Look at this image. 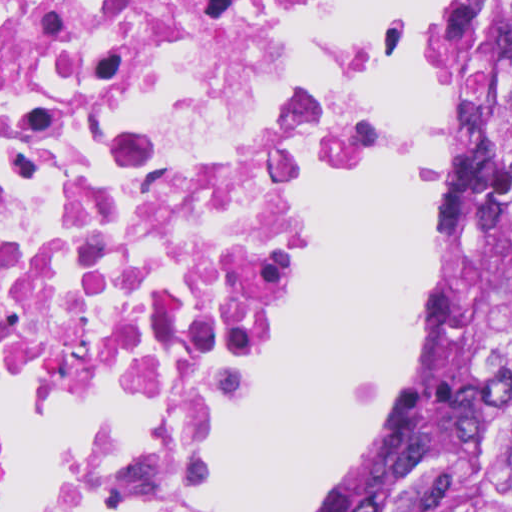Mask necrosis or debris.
Returning a JSON list of instances; mask_svg holds the SVG:
<instances>
[{
  "instance_id": "necrosis-or-debris-1",
  "label": "necrosis or debris",
  "mask_w": 512,
  "mask_h": 512,
  "mask_svg": "<svg viewBox=\"0 0 512 512\" xmlns=\"http://www.w3.org/2000/svg\"><path fill=\"white\" fill-rule=\"evenodd\" d=\"M353 1L0 0V512H205L383 146Z\"/></svg>"
}]
</instances>
